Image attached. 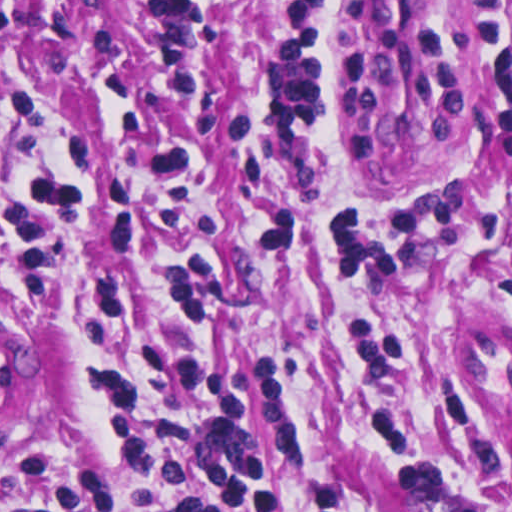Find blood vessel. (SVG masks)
Returning a JSON list of instances; mask_svg holds the SVG:
<instances>
[{"mask_svg": "<svg viewBox=\"0 0 512 512\" xmlns=\"http://www.w3.org/2000/svg\"><path fill=\"white\" fill-rule=\"evenodd\" d=\"M342 56L359 118L380 152L420 170L473 157L471 100L448 1H354ZM25 394V356L0 335V398Z\"/></svg>", "mask_w": 512, "mask_h": 512, "instance_id": "blood-vessel-1", "label": "blood vessel"}]
</instances>
